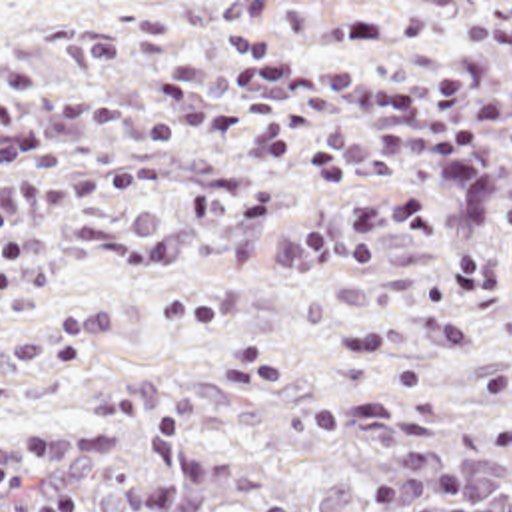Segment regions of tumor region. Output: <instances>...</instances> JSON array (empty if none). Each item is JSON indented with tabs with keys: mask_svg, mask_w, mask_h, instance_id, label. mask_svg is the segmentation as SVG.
Instances as JSON below:
<instances>
[{
	"mask_svg": "<svg viewBox=\"0 0 512 512\" xmlns=\"http://www.w3.org/2000/svg\"><path fill=\"white\" fill-rule=\"evenodd\" d=\"M511 407L118 389L0 425V512H512Z\"/></svg>",
	"mask_w": 512,
	"mask_h": 512,
	"instance_id": "tumor-region-1",
	"label": "tumor region"
}]
</instances>
